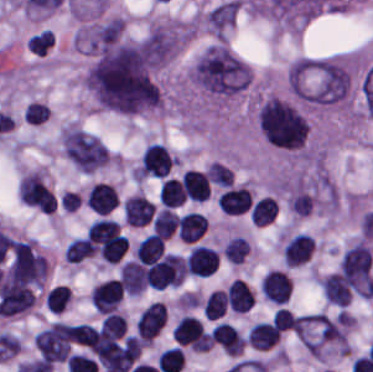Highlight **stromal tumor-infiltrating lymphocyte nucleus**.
Wrapping results in <instances>:
<instances>
[{"mask_svg":"<svg viewBox=\"0 0 373 372\" xmlns=\"http://www.w3.org/2000/svg\"><path fill=\"white\" fill-rule=\"evenodd\" d=\"M164 302L150 301L138 314L135 329L142 342H151L164 326Z\"/></svg>","mask_w":373,"mask_h":372,"instance_id":"stromal-tumor-infiltrating-lymphocyte-nucleus-1","label":"stromal tumor-infiltrating lymphocyte nucleus"},{"mask_svg":"<svg viewBox=\"0 0 373 372\" xmlns=\"http://www.w3.org/2000/svg\"><path fill=\"white\" fill-rule=\"evenodd\" d=\"M218 255L216 250L202 244L190 248L185 261V270L189 275L207 277L216 272Z\"/></svg>","mask_w":373,"mask_h":372,"instance_id":"stromal-tumor-infiltrating-lymphocyte-nucleus-2","label":"stromal tumor-infiltrating lymphocyte nucleus"},{"mask_svg":"<svg viewBox=\"0 0 373 372\" xmlns=\"http://www.w3.org/2000/svg\"><path fill=\"white\" fill-rule=\"evenodd\" d=\"M84 202L97 215H108L118 206L119 198L113 185L97 182L88 189Z\"/></svg>","mask_w":373,"mask_h":372,"instance_id":"stromal-tumor-infiltrating-lymphocyte-nucleus-3","label":"stromal tumor-infiltrating lymphocyte nucleus"},{"mask_svg":"<svg viewBox=\"0 0 373 372\" xmlns=\"http://www.w3.org/2000/svg\"><path fill=\"white\" fill-rule=\"evenodd\" d=\"M171 337L179 346L205 349V331L194 316L184 315L175 325Z\"/></svg>","mask_w":373,"mask_h":372,"instance_id":"stromal-tumor-infiltrating-lymphocyte-nucleus-4","label":"stromal tumor-infiltrating lymphocyte nucleus"},{"mask_svg":"<svg viewBox=\"0 0 373 372\" xmlns=\"http://www.w3.org/2000/svg\"><path fill=\"white\" fill-rule=\"evenodd\" d=\"M216 203L224 214H243L251 208V190L242 187H229L218 195Z\"/></svg>","mask_w":373,"mask_h":372,"instance_id":"stromal-tumor-infiltrating-lymphocyte-nucleus-5","label":"stromal tumor-infiltrating lymphocyte nucleus"},{"mask_svg":"<svg viewBox=\"0 0 373 372\" xmlns=\"http://www.w3.org/2000/svg\"><path fill=\"white\" fill-rule=\"evenodd\" d=\"M315 241L304 232H299L287 240L282 255L287 267H297L306 263Z\"/></svg>","mask_w":373,"mask_h":372,"instance_id":"stromal-tumor-infiltrating-lymphocyte-nucleus-6","label":"stromal tumor-infiltrating lymphocyte nucleus"},{"mask_svg":"<svg viewBox=\"0 0 373 372\" xmlns=\"http://www.w3.org/2000/svg\"><path fill=\"white\" fill-rule=\"evenodd\" d=\"M290 294V281L281 271L268 270L262 279L261 295L272 303H286Z\"/></svg>","mask_w":373,"mask_h":372,"instance_id":"stromal-tumor-infiltrating-lymphocyte-nucleus-7","label":"stromal tumor-infiltrating lymphocyte nucleus"},{"mask_svg":"<svg viewBox=\"0 0 373 372\" xmlns=\"http://www.w3.org/2000/svg\"><path fill=\"white\" fill-rule=\"evenodd\" d=\"M181 191L185 199L202 202L210 194V186L204 172L188 169L180 178Z\"/></svg>","mask_w":373,"mask_h":372,"instance_id":"stromal-tumor-infiltrating-lymphocyte-nucleus-8","label":"stromal tumor-infiltrating lymphocyte nucleus"},{"mask_svg":"<svg viewBox=\"0 0 373 372\" xmlns=\"http://www.w3.org/2000/svg\"><path fill=\"white\" fill-rule=\"evenodd\" d=\"M226 302L235 312H247L254 303L253 291L246 282L235 277L226 286Z\"/></svg>","mask_w":373,"mask_h":372,"instance_id":"stromal-tumor-infiltrating-lymphocyte-nucleus-9","label":"stromal tumor-infiltrating lymphocyte nucleus"},{"mask_svg":"<svg viewBox=\"0 0 373 372\" xmlns=\"http://www.w3.org/2000/svg\"><path fill=\"white\" fill-rule=\"evenodd\" d=\"M281 331L264 321H257L249 331L246 342L257 351H268L276 346Z\"/></svg>","mask_w":373,"mask_h":372,"instance_id":"stromal-tumor-infiltrating-lymphocyte-nucleus-10","label":"stromal tumor-infiltrating lymphocyte nucleus"},{"mask_svg":"<svg viewBox=\"0 0 373 372\" xmlns=\"http://www.w3.org/2000/svg\"><path fill=\"white\" fill-rule=\"evenodd\" d=\"M207 219L194 211L184 213L178 221L179 239L186 242H196L206 231Z\"/></svg>","mask_w":373,"mask_h":372,"instance_id":"stromal-tumor-infiltrating-lymphocyte-nucleus-11","label":"stromal tumor-infiltrating lymphocyte nucleus"},{"mask_svg":"<svg viewBox=\"0 0 373 372\" xmlns=\"http://www.w3.org/2000/svg\"><path fill=\"white\" fill-rule=\"evenodd\" d=\"M319 288L327 300L335 305H349L350 291L344 283L332 273L319 279Z\"/></svg>","mask_w":373,"mask_h":372,"instance_id":"stromal-tumor-infiltrating-lymphocyte-nucleus-12","label":"stromal tumor-infiltrating lymphocyte nucleus"},{"mask_svg":"<svg viewBox=\"0 0 373 372\" xmlns=\"http://www.w3.org/2000/svg\"><path fill=\"white\" fill-rule=\"evenodd\" d=\"M278 212V202L272 195H265L256 200L250 208L252 224L266 225Z\"/></svg>","mask_w":373,"mask_h":372,"instance_id":"stromal-tumor-infiltrating-lymphocyte-nucleus-13","label":"stromal tumor-infiltrating lymphocyte nucleus"},{"mask_svg":"<svg viewBox=\"0 0 373 372\" xmlns=\"http://www.w3.org/2000/svg\"><path fill=\"white\" fill-rule=\"evenodd\" d=\"M162 255L163 243L151 233L139 240L134 248V259L140 264L155 261Z\"/></svg>","mask_w":373,"mask_h":372,"instance_id":"stromal-tumor-infiltrating-lymphocyte-nucleus-14","label":"stromal tumor-infiltrating lymphocyte nucleus"},{"mask_svg":"<svg viewBox=\"0 0 373 372\" xmlns=\"http://www.w3.org/2000/svg\"><path fill=\"white\" fill-rule=\"evenodd\" d=\"M176 221V213L171 209L162 207L153 215L150 225L154 234L165 240L171 236Z\"/></svg>","mask_w":373,"mask_h":372,"instance_id":"stromal-tumor-infiltrating-lymphocyte-nucleus-15","label":"stromal tumor-infiltrating lymphocyte nucleus"},{"mask_svg":"<svg viewBox=\"0 0 373 372\" xmlns=\"http://www.w3.org/2000/svg\"><path fill=\"white\" fill-rule=\"evenodd\" d=\"M91 256H93V253L85 235L72 238L63 252V260L67 264H79Z\"/></svg>","mask_w":373,"mask_h":372,"instance_id":"stromal-tumor-infiltrating-lymphocyte-nucleus-16","label":"stromal tumor-infiltrating lymphocyte nucleus"},{"mask_svg":"<svg viewBox=\"0 0 373 372\" xmlns=\"http://www.w3.org/2000/svg\"><path fill=\"white\" fill-rule=\"evenodd\" d=\"M185 200L181 185L174 178L162 179L159 188L160 204L176 208Z\"/></svg>","mask_w":373,"mask_h":372,"instance_id":"stromal-tumor-infiltrating-lymphocyte-nucleus-17","label":"stromal tumor-infiltrating lymphocyte nucleus"},{"mask_svg":"<svg viewBox=\"0 0 373 372\" xmlns=\"http://www.w3.org/2000/svg\"><path fill=\"white\" fill-rule=\"evenodd\" d=\"M72 298L68 286L56 285L45 294V306L47 311L62 313Z\"/></svg>","mask_w":373,"mask_h":372,"instance_id":"stromal-tumor-infiltrating-lymphocyte-nucleus-18","label":"stromal tumor-infiltrating lymphocyte nucleus"},{"mask_svg":"<svg viewBox=\"0 0 373 372\" xmlns=\"http://www.w3.org/2000/svg\"><path fill=\"white\" fill-rule=\"evenodd\" d=\"M226 298L225 291L212 290L205 298L203 313L209 319L222 317L225 313Z\"/></svg>","mask_w":373,"mask_h":372,"instance_id":"stromal-tumor-infiltrating-lymphocyte-nucleus-19","label":"stromal tumor-infiltrating lymphocyte nucleus"},{"mask_svg":"<svg viewBox=\"0 0 373 372\" xmlns=\"http://www.w3.org/2000/svg\"><path fill=\"white\" fill-rule=\"evenodd\" d=\"M206 174L210 183L221 188H228L233 176L230 168L213 161L211 162Z\"/></svg>","mask_w":373,"mask_h":372,"instance_id":"stromal-tumor-infiltrating-lymphocyte-nucleus-20","label":"stromal tumor-infiltrating lymphocyte nucleus"},{"mask_svg":"<svg viewBox=\"0 0 373 372\" xmlns=\"http://www.w3.org/2000/svg\"><path fill=\"white\" fill-rule=\"evenodd\" d=\"M296 322L297 320L286 307H278L271 319L272 326L282 332L292 331Z\"/></svg>","mask_w":373,"mask_h":372,"instance_id":"stromal-tumor-infiltrating-lymphocyte-nucleus-21","label":"stromal tumor-infiltrating lymphocyte nucleus"},{"mask_svg":"<svg viewBox=\"0 0 373 372\" xmlns=\"http://www.w3.org/2000/svg\"><path fill=\"white\" fill-rule=\"evenodd\" d=\"M49 111L46 103L30 101L26 103L24 117L26 123H40L46 119Z\"/></svg>","mask_w":373,"mask_h":372,"instance_id":"stromal-tumor-infiltrating-lymphocyte-nucleus-22","label":"stromal tumor-infiltrating lymphocyte nucleus"}]
</instances>
